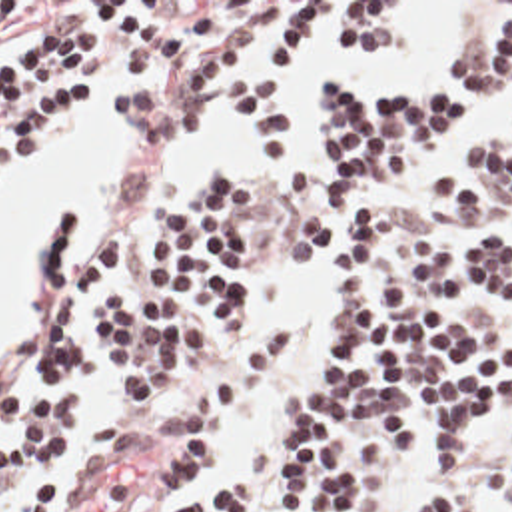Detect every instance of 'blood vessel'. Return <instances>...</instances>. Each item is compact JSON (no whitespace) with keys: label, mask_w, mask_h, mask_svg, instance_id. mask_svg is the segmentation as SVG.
<instances>
[{"label":"blood vessel","mask_w":512,"mask_h":512,"mask_svg":"<svg viewBox=\"0 0 512 512\" xmlns=\"http://www.w3.org/2000/svg\"><path fill=\"white\" fill-rule=\"evenodd\" d=\"M143 473L145 443L129 433L67 485L59 512H127Z\"/></svg>","instance_id":"8fb6f2fc"}]
</instances>
